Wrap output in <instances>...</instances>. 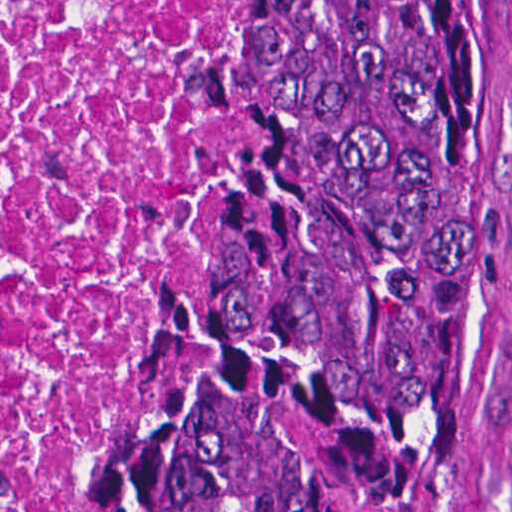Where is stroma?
Masks as SVG:
<instances>
[{
	"mask_svg": "<svg viewBox=\"0 0 512 512\" xmlns=\"http://www.w3.org/2000/svg\"><path fill=\"white\" fill-rule=\"evenodd\" d=\"M481 3L485 21V166L512 388V0H481ZM244 12L245 0H236V126L237 58ZM195 219L196 216L183 234L110 416L128 389L147 347L167 286L192 239ZM88 459L48 512H62ZM506 512H512V493Z\"/></svg>",
	"mask_w": 512,
	"mask_h": 512,
	"instance_id": "stroma-1",
	"label": "stroma"
}]
</instances>
